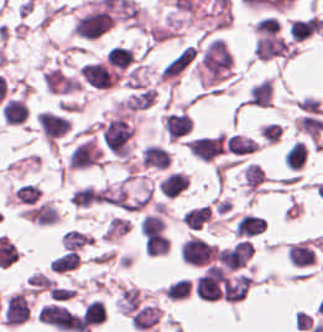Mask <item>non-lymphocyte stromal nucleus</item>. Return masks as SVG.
<instances>
[{
  "mask_svg": "<svg viewBox=\"0 0 323 332\" xmlns=\"http://www.w3.org/2000/svg\"><path fill=\"white\" fill-rule=\"evenodd\" d=\"M197 49L189 45L173 57L167 65L163 68L160 79L170 80L174 79L181 73L194 59Z\"/></svg>",
  "mask_w": 323,
  "mask_h": 332,
  "instance_id": "1",
  "label": "non-lymphocyte stromal nucleus"
}]
</instances>
